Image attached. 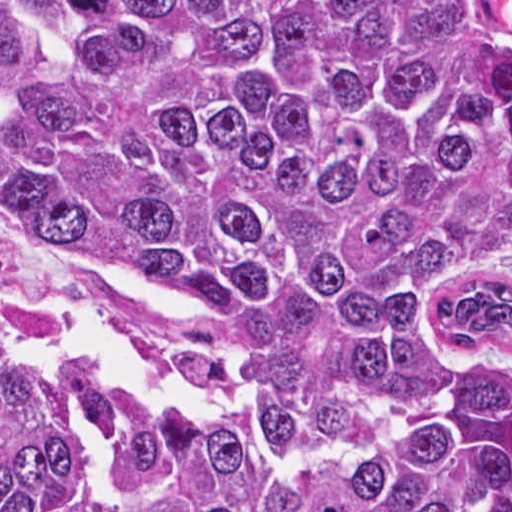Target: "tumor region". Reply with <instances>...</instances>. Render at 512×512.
<instances>
[{
  "label": "tumor region",
  "instance_id": "e687c5a6",
  "mask_svg": "<svg viewBox=\"0 0 512 512\" xmlns=\"http://www.w3.org/2000/svg\"><path fill=\"white\" fill-rule=\"evenodd\" d=\"M489 1H0V512H512Z\"/></svg>",
  "mask_w": 512,
  "mask_h": 512
}]
</instances>
